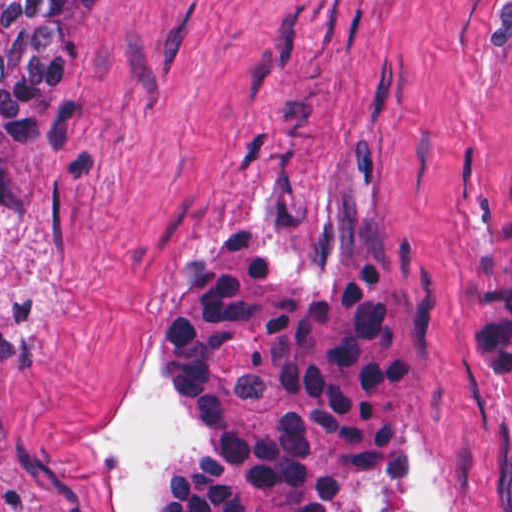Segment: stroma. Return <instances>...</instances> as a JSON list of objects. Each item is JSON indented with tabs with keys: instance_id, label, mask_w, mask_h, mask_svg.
<instances>
[{
	"instance_id": "1",
	"label": "stroma",
	"mask_w": 512,
	"mask_h": 512,
	"mask_svg": "<svg viewBox=\"0 0 512 512\" xmlns=\"http://www.w3.org/2000/svg\"><path fill=\"white\" fill-rule=\"evenodd\" d=\"M511 194L512 0H86L0 227V512H151L196 443L154 397L180 261L314 262L373 209L425 263L391 512H512L465 320Z\"/></svg>"
}]
</instances>
